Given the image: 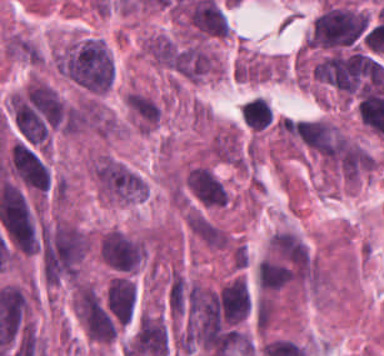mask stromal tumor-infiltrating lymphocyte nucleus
Listing matches in <instances>:
<instances>
[{"label": "stromal tumor-infiltrating lymphocyte nucleus", "mask_w": 384, "mask_h": 356, "mask_svg": "<svg viewBox=\"0 0 384 356\" xmlns=\"http://www.w3.org/2000/svg\"><path fill=\"white\" fill-rule=\"evenodd\" d=\"M241 117L252 130H266L273 120V112L267 98L254 95L247 98L240 108Z\"/></svg>", "instance_id": "obj_1"}]
</instances>
